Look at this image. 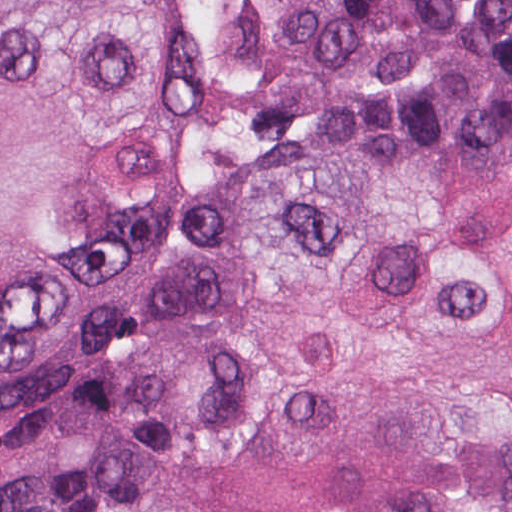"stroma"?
I'll return each mask as SVG.
<instances>
[{
	"instance_id": "obj_1",
	"label": "stroma",
	"mask_w": 512,
	"mask_h": 512,
	"mask_svg": "<svg viewBox=\"0 0 512 512\" xmlns=\"http://www.w3.org/2000/svg\"><path fill=\"white\" fill-rule=\"evenodd\" d=\"M187 1L201 82V130L146 273L132 296L128 317L105 360L87 381L49 400L0 411V431L40 422L80 403L128 365L153 313L170 235L203 181L231 163L251 160L322 126L314 111L277 102L263 92L243 98L215 70V34L195 0Z\"/></svg>"
}]
</instances>
